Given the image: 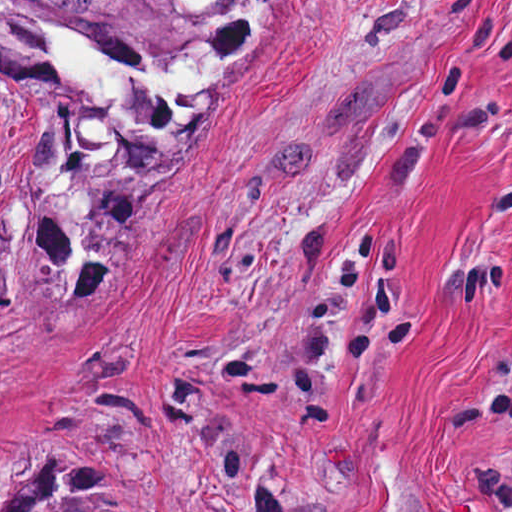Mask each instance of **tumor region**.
<instances>
[{"label": "tumor region", "mask_w": 512, "mask_h": 512, "mask_svg": "<svg viewBox=\"0 0 512 512\" xmlns=\"http://www.w3.org/2000/svg\"><path fill=\"white\" fill-rule=\"evenodd\" d=\"M226 2L0 0V62L47 69L54 38H93L117 65L193 59ZM22 462L0 487V512H142L89 464L40 455Z\"/></svg>", "instance_id": "e687c5a6"}]
</instances>
